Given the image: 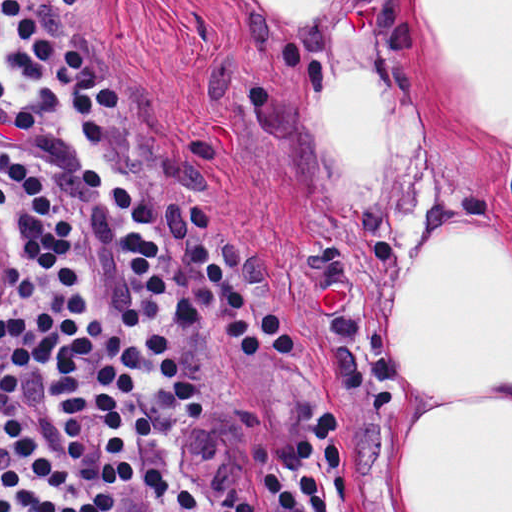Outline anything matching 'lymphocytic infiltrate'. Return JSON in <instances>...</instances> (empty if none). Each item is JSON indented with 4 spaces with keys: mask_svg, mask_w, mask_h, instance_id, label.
<instances>
[{
    "mask_svg": "<svg viewBox=\"0 0 512 512\" xmlns=\"http://www.w3.org/2000/svg\"><path fill=\"white\" fill-rule=\"evenodd\" d=\"M0 12L25 49L9 59L25 70L29 98L18 100L0 78V104L16 109L31 130L73 94L86 144L102 141L99 112L127 110L115 77L30 0H0ZM81 178L104 189L129 230L122 237L133 270L153 295H167L152 264L159 244L142 233L158 216L124 187H111L96 168ZM0 201L15 217L23 240L44 260L24 254V291L12 313L0 317V512H150V479L138 459V439L151 427L140 400V378L153 373L190 424L204 418V400L163 333L142 349L127 337H108L96 298L73 264L78 236L53 187L9 146L0 143ZM191 257L219 296L223 334L245 355H283L292 331L272 304H252L233 285L221 252L204 234ZM180 512H211L184 484ZM328 512L346 495L342 431L337 415L316 412L263 459L252 494L213 512Z\"/></svg>",
    "mask_w": 512,
    "mask_h": 512,
    "instance_id": "f902f5d3",
    "label": "lymphocytic infiltrate"
}]
</instances>
